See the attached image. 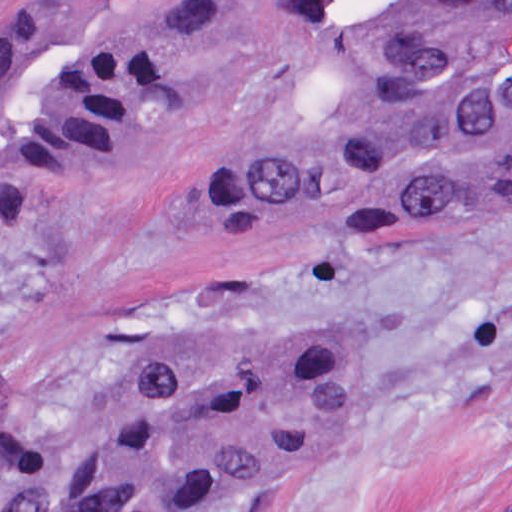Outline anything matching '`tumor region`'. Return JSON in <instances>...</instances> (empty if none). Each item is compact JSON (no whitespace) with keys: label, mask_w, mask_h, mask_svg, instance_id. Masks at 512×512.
Here are the masks:
<instances>
[{"label":"tumor region","mask_w":512,"mask_h":512,"mask_svg":"<svg viewBox=\"0 0 512 512\" xmlns=\"http://www.w3.org/2000/svg\"><path fill=\"white\" fill-rule=\"evenodd\" d=\"M229 30L225 0H37L0 37L11 215L130 166ZM319 120L215 176L217 212L313 239H397L512 202V0L336 73ZM350 360L320 338L158 356L54 418L0 430V468L49 486L21 512H216L339 436Z\"/></svg>","instance_id":"tumor-region-1"}]
</instances>
